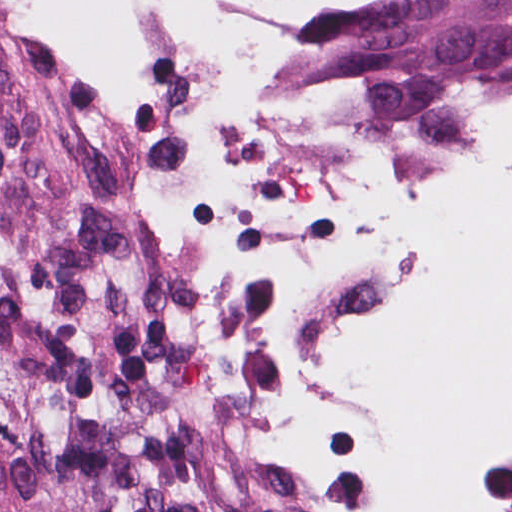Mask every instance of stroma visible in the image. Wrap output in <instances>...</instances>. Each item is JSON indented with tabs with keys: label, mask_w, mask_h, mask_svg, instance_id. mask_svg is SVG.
Segmentation results:
<instances>
[{
	"label": "stroma",
	"mask_w": 512,
	"mask_h": 512,
	"mask_svg": "<svg viewBox=\"0 0 512 512\" xmlns=\"http://www.w3.org/2000/svg\"><path fill=\"white\" fill-rule=\"evenodd\" d=\"M215 1L246 3L263 20V26L250 42L246 63L240 70L255 71L277 48L298 39L314 6L335 0ZM0 44L19 59L51 118L60 77L110 66L95 49L66 41L22 14L18 0H0ZM292 72L316 77H339L320 70ZM163 270L184 291L246 371L262 386L228 319L204 295Z\"/></svg>",
	"instance_id": "1"
}]
</instances>
